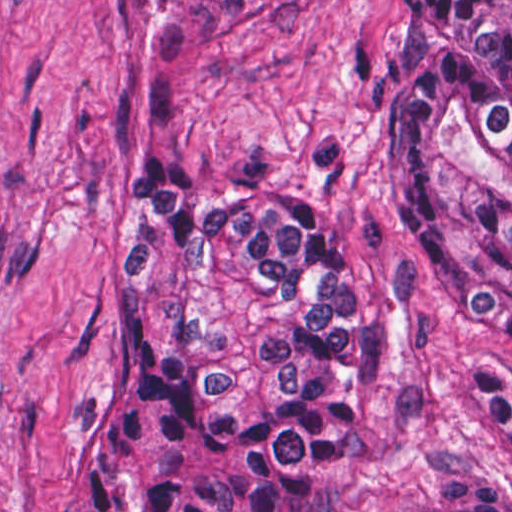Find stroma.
Returning a JSON list of instances; mask_svg holds the SVG:
<instances>
[{"instance_id": "obj_1", "label": "stroma", "mask_w": 512, "mask_h": 512, "mask_svg": "<svg viewBox=\"0 0 512 512\" xmlns=\"http://www.w3.org/2000/svg\"><path fill=\"white\" fill-rule=\"evenodd\" d=\"M401 0H0V512H73L123 402L112 277L132 180L296 196L377 289V378L326 512L512 484V367L457 300L397 154Z\"/></svg>"}]
</instances>
